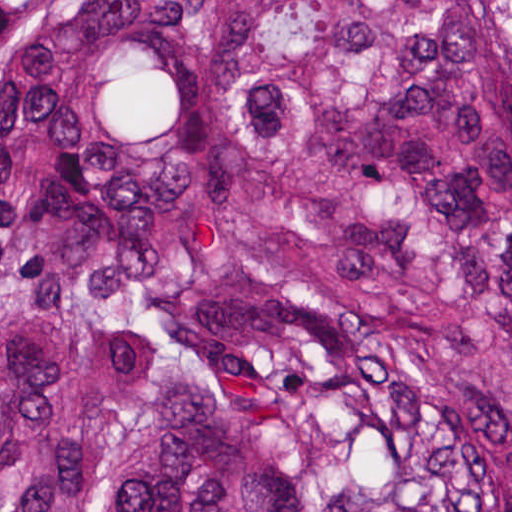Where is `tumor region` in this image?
Wrapping results in <instances>:
<instances>
[{"label": "tumor region", "mask_w": 512, "mask_h": 512, "mask_svg": "<svg viewBox=\"0 0 512 512\" xmlns=\"http://www.w3.org/2000/svg\"><path fill=\"white\" fill-rule=\"evenodd\" d=\"M0 512H512V0H0Z\"/></svg>", "instance_id": "e687c5a6"}]
</instances>
